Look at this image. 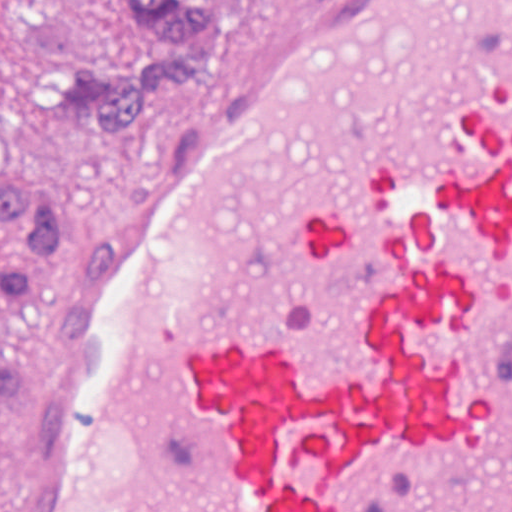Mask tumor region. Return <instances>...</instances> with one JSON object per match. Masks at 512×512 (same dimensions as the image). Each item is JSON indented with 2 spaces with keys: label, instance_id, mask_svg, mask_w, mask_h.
Returning <instances> with one entry per match:
<instances>
[{
  "label": "tumor region",
  "instance_id": "e687c5a6",
  "mask_svg": "<svg viewBox=\"0 0 512 512\" xmlns=\"http://www.w3.org/2000/svg\"><path fill=\"white\" fill-rule=\"evenodd\" d=\"M32 104L66 106L127 139L217 58L224 0H0ZM71 235L58 201L36 186L0 189V304L25 313L35 269L60 259ZM14 366H0V401Z\"/></svg>",
  "mask_w": 512,
  "mask_h": 512
}]
</instances>
